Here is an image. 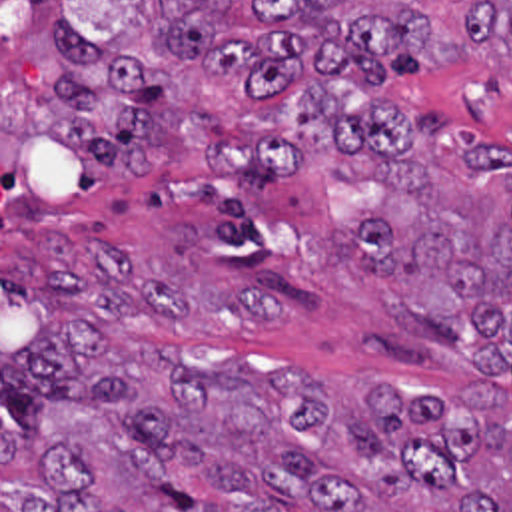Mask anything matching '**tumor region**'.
Returning a JSON list of instances; mask_svg holds the SVG:
<instances>
[{
	"mask_svg": "<svg viewBox=\"0 0 512 512\" xmlns=\"http://www.w3.org/2000/svg\"><path fill=\"white\" fill-rule=\"evenodd\" d=\"M252 0L262 33L218 37L230 0H150L164 59L244 85L214 119L150 61L48 27L58 107L48 133L92 171L140 183L198 161L230 187H276L315 155L373 163L387 195L347 245L405 320L477 368L512 376V157L469 131L319 81L387 85L457 67L453 33L405 7ZM467 41L512 45V0L461 9ZM0 512H512V414L467 384L397 396L371 382L337 416L307 372L184 368L156 348L120 283L90 271L0 267Z\"/></svg>",
	"mask_w": 512,
	"mask_h": 512,
	"instance_id": "tumor-region-1",
	"label": "tumor region"
}]
</instances>
